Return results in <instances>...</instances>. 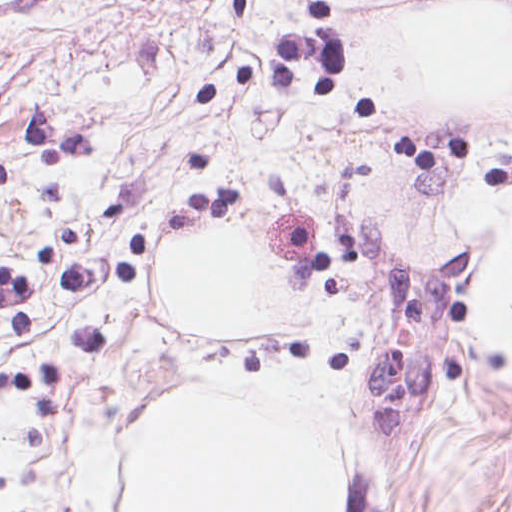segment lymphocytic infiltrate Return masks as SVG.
<instances>
[{
  "mask_svg": "<svg viewBox=\"0 0 512 512\" xmlns=\"http://www.w3.org/2000/svg\"><path fill=\"white\" fill-rule=\"evenodd\" d=\"M189 192L203 211L236 210V190ZM31 287L26 278L0 265V322L28 337H37V327L29 309Z\"/></svg>",
  "mask_w": 512,
  "mask_h": 512,
  "instance_id": "1",
  "label": "lymphocytic infiltrate"
}]
</instances>
